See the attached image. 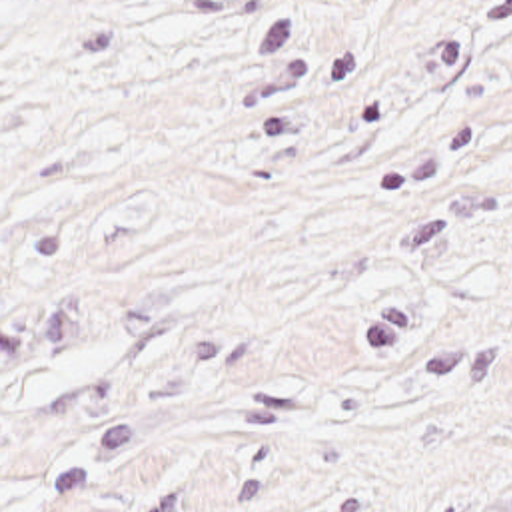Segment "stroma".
Wrapping results in <instances>:
<instances>
[{
	"label": "stroma",
	"instance_id": "stroma-1",
	"mask_svg": "<svg viewBox=\"0 0 512 512\" xmlns=\"http://www.w3.org/2000/svg\"><path fill=\"white\" fill-rule=\"evenodd\" d=\"M0 512H512V0H0Z\"/></svg>",
	"mask_w": 512,
	"mask_h": 512
}]
</instances>
